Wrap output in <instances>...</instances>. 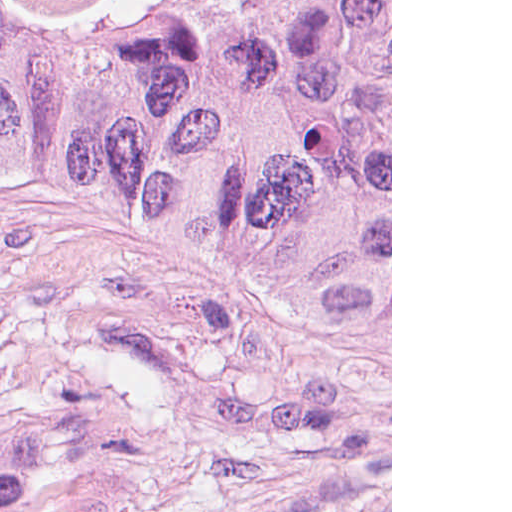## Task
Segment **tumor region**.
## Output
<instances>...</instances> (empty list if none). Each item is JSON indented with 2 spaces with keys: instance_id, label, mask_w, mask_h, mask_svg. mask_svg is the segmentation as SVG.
Wrapping results in <instances>:
<instances>
[{
  "instance_id": "1",
  "label": "tumor region",
  "mask_w": 512,
  "mask_h": 512,
  "mask_svg": "<svg viewBox=\"0 0 512 512\" xmlns=\"http://www.w3.org/2000/svg\"><path fill=\"white\" fill-rule=\"evenodd\" d=\"M0 211L176 271L237 340L390 371V0H0ZM161 378L0 357V512H122Z\"/></svg>"
}]
</instances>
